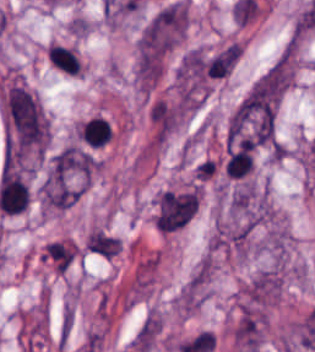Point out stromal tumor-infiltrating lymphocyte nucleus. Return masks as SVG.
I'll use <instances>...</instances> for the list:
<instances>
[{
    "instance_id": "stromal-tumor-infiltrating-lymphocyte-nucleus-2",
    "label": "stromal tumor-infiltrating lymphocyte nucleus",
    "mask_w": 315,
    "mask_h": 352,
    "mask_svg": "<svg viewBox=\"0 0 315 352\" xmlns=\"http://www.w3.org/2000/svg\"><path fill=\"white\" fill-rule=\"evenodd\" d=\"M48 62L57 70L77 74L80 70V60L75 50L58 43L47 47Z\"/></svg>"
},
{
    "instance_id": "stromal-tumor-infiltrating-lymphocyte-nucleus-1",
    "label": "stromal tumor-infiltrating lymphocyte nucleus",
    "mask_w": 315,
    "mask_h": 352,
    "mask_svg": "<svg viewBox=\"0 0 315 352\" xmlns=\"http://www.w3.org/2000/svg\"><path fill=\"white\" fill-rule=\"evenodd\" d=\"M80 143L89 148H102L112 135L111 123L107 118L91 116L77 131Z\"/></svg>"
}]
</instances>
